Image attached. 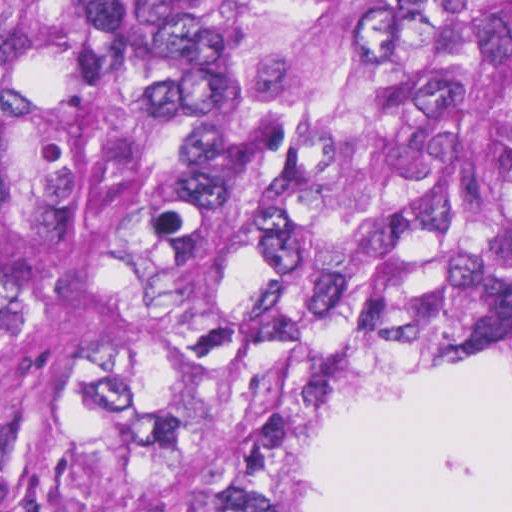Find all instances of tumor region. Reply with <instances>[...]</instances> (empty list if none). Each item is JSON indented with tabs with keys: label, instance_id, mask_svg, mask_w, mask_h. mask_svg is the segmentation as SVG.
<instances>
[{
	"label": "tumor region",
	"instance_id": "e687c5a6",
	"mask_svg": "<svg viewBox=\"0 0 512 512\" xmlns=\"http://www.w3.org/2000/svg\"><path fill=\"white\" fill-rule=\"evenodd\" d=\"M408 369H512V0H0V512H306Z\"/></svg>",
	"mask_w": 512,
	"mask_h": 512
}]
</instances>
